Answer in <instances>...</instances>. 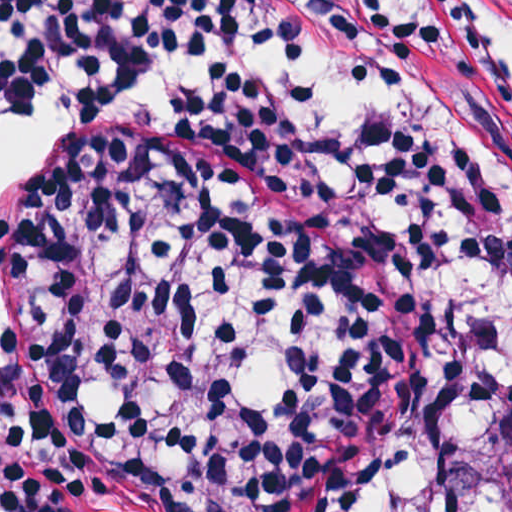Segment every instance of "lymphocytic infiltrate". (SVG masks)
<instances>
[{
    "label": "lymphocytic infiltrate",
    "mask_w": 512,
    "mask_h": 512,
    "mask_svg": "<svg viewBox=\"0 0 512 512\" xmlns=\"http://www.w3.org/2000/svg\"><path fill=\"white\" fill-rule=\"evenodd\" d=\"M59 104L166 110L276 157L346 258L436 299L392 443L339 512H496L512 407V182L387 103L311 0H0V140ZM51 153L47 154L49 156ZM0 219V251L46 158ZM0 512H131L0 364Z\"/></svg>",
    "instance_id": "lymphocytic-infiltrate-1"
}]
</instances>
